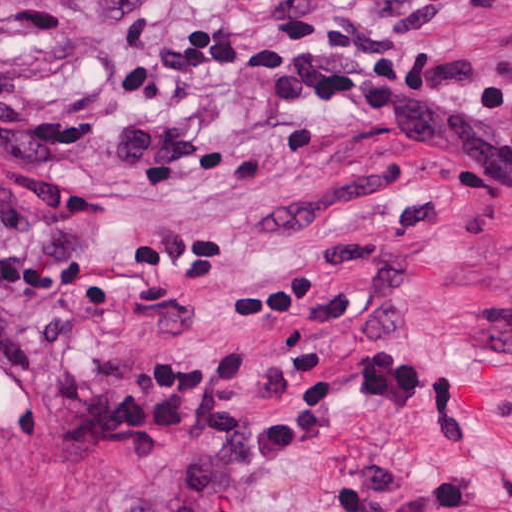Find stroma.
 Instances as JSON below:
<instances>
[{"mask_svg":"<svg viewBox=\"0 0 512 512\" xmlns=\"http://www.w3.org/2000/svg\"><path fill=\"white\" fill-rule=\"evenodd\" d=\"M175 19H340L387 27L378 0H0V512H124L151 449L65 454L78 419L54 384L92 368H167L206 349L262 352L260 381L222 417L279 414L284 357L334 365L397 347L465 373L481 429L430 438L355 415L340 457L281 465L246 512H324L362 478L357 451L469 469L471 512H512V215L455 191L442 165L311 102L250 80H200L202 105L246 160L148 178L105 160L125 114L115 68ZM442 29L512 47V0H467ZM428 205L435 229L356 255L299 298L229 303L296 273L332 240L379 232Z\"/></svg>","mask_w":512,"mask_h":512,"instance_id":"1","label":"stroma"}]
</instances>
